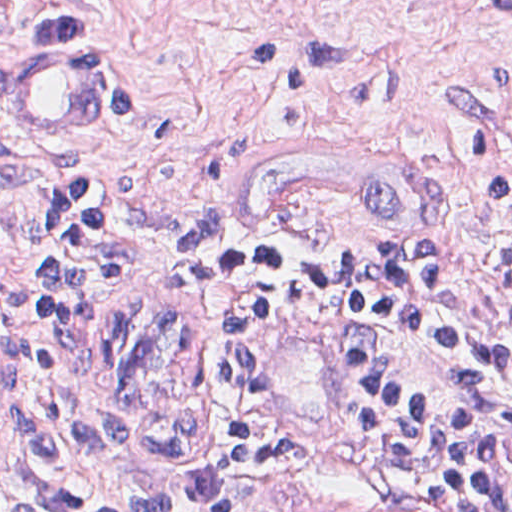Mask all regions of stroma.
Returning a JSON list of instances; mask_svg holds the SVG:
<instances>
[{"instance_id":"1","label":"stroma","mask_w":512,"mask_h":512,"mask_svg":"<svg viewBox=\"0 0 512 512\" xmlns=\"http://www.w3.org/2000/svg\"><path fill=\"white\" fill-rule=\"evenodd\" d=\"M90 29L120 59L108 116L65 140H26L0 112V288L32 266L64 194L101 185L177 206L173 268L117 284L100 317L114 393L146 416L208 383L211 259L248 245L286 262L371 259L409 249L512 245V204L489 186L512 166V0H0V75L52 37ZM310 117L385 120L447 156L435 221L318 209L280 231L228 221L240 144ZM19 366V340L0 327ZM264 421L303 455V495L283 512H453L397 472L357 421L331 331L292 319L270 357ZM0 512H81L58 484L27 414L0 463Z\"/></svg>"}]
</instances>
